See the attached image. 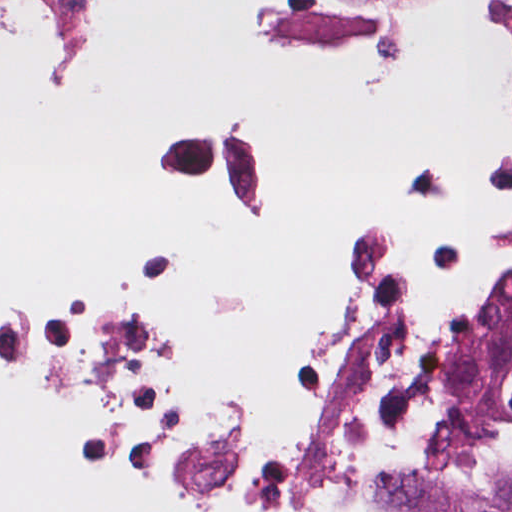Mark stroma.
<instances>
[{"mask_svg": "<svg viewBox=\"0 0 512 512\" xmlns=\"http://www.w3.org/2000/svg\"><path fill=\"white\" fill-rule=\"evenodd\" d=\"M511 5L512 0H244L239 30L242 44L253 56H315L397 65L415 59L424 44V24L438 13L461 12L476 18L498 46V107L482 159L499 147L508 132V53L501 21ZM14 8H31L47 36L44 54L34 65L37 97L74 100L103 86L109 71V27L91 0H0V41ZM184 115L225 114L156 116L144 128L138 145L168 187L192 200L162 164L150 131ZM417 167L439 166L411 158L395 160L381 184L397 172ZM510 374L512 329L483 383L490 391ZM463 478L491 490L505 484Z\"/></svg>", "mask_w": 512, "mask_h": 512, "instance_id": "stroma-1", "label": "stroma"}]
</instances>
